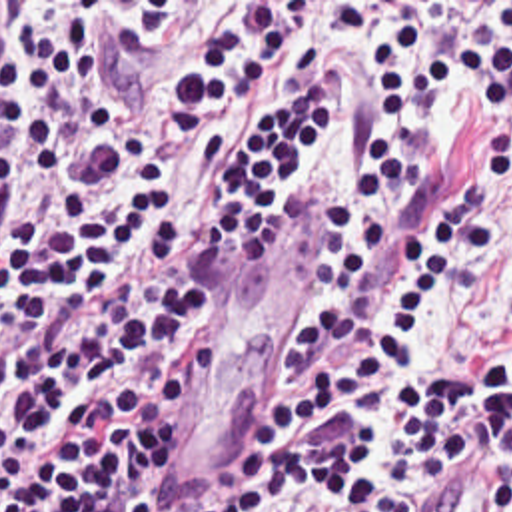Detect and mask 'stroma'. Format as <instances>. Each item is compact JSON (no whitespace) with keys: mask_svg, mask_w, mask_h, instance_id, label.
Wrapping results in <instances>:
<instances>
[{"mask_svg":"<svg viewBox=\"0 0 512 512\" xmlns=\"http://www.w3.org/2000/svg\"><path fill=\"white\" fill-rule=\"evenodd\" d=\"M14 2V40L28 24L84 22L102 32L108 66L122 88L140 80L194 22L258 6H304L306 36L260 78L208 142L176 160L168 192H194L200 176L232 142L262 120L292 88L314 54L335 64L333 122L320 166L306 176L280 220L252 242L224 250L232 305L204 329L218 335L224 367L212 379L184 429V471L156 491L162 512H202L220 499L242 459L260 395L282 363V323L304 290L322 232V212L365 158L371 128V64L385 24L419 6L455 14L479 2L512 0H0Z\"/></svg>","mask_w":512,"mask_h":512,"instance_id":"1","label":"stroma"}]
</instances>
